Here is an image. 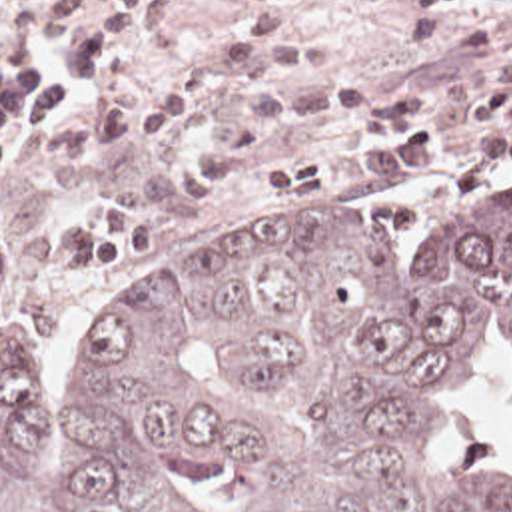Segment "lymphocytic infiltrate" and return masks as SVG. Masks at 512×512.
<instances>
[{
    "mask_svg": "<svg viewBox=\"0 0 512 512\" xmlns=\"http://www.w3.org/2000/svg\"><path fill=\"white\" fill-rule=\"evenodd\" d=\"M463 0H401L411 17H433ZM471 109L477 119L503 125L473 141L479 160H512V89H489L473 95Z\"/></svg>",
    "mask_w": 512,
    "mask_h": 512,
    "instance_id": "1",
    "label": "lymphocytic infiltrate"
}]
</instances>
